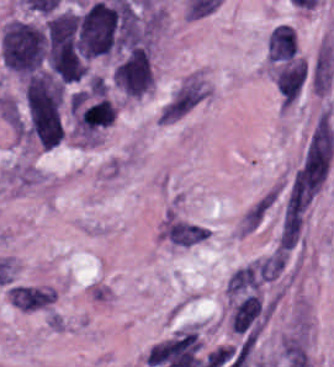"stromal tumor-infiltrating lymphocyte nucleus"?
<instances>
[{
    "label": "stromal tumor-infiltrating lymphocyte nucleus",
    "mask_w": 334,
    "mask_h": 367,
    "mask_svg": "<svg viewBox=\"0 0 334 367\" xmlns=\"http://www.w3.org/2000/svg\"><path fill=\"white\" fill-rule=\"evenodd\" d=\"M307 78L308 65L297 55L274 67L273 81L283 107L289 108L297 101Z\"/></svg>",
    "instance_id": "obj_1"
}]
</instances>
